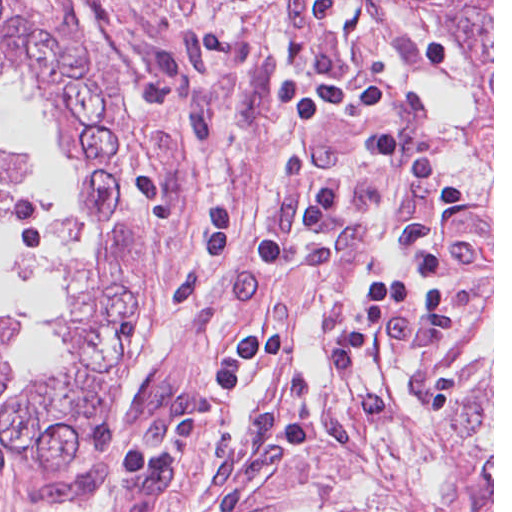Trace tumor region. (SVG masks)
<instances>
[{"mask_svg":"<svg viewBox=\"0 0 512 512\" xmlns=\"http://www.w3.org/2000/svg\"><path fill=\"white\" fill-rule=\"evenodd\" d=\"M0 453H7L19 462L1 405H0ZM20 463V462H19Z\"/></svg>","mask_w":512,"mask_h":512,"instance_id":"e687c5a6","label":"tumor region"}]
</instances>
